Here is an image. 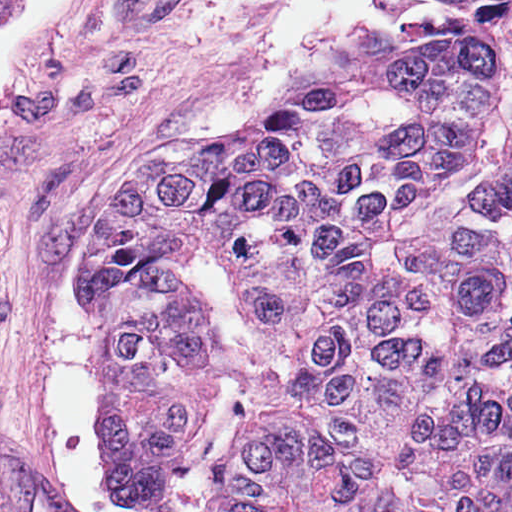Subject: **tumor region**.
Listing matches in <instances>:
<instances>
[{
    "instance_id": "e687c5a6",
    "label": "tumor region",
    "mask_w": 512,
    "mask_h": 512,
    "mask_svg": "<svg viewBox=\"0 0 512 512\" xmlns=\"http://www.w3.org/2000/svg\"><path fill=\"white\" fill-rule=\"evenodd\" d=\"M153 159L310 512H512V0H427Z\"/></svg>"
}]
</instances>
